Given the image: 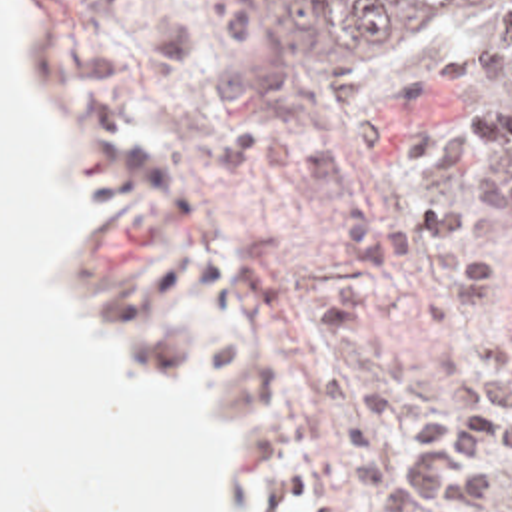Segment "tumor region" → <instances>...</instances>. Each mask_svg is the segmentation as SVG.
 Masks as SVG:
<instances>
[{"label":"tumor region","mask_w":512,"mask_h":512,"mask_svg":"<svg viewBox=\"0 0 512 512\" xmlns=\"http://www.w3.org/2000/svg\"><path fill=\"white\" fill-rule=\"evenodd\" d=\"M274 41L334 63L394 35L452 27L498 71L512 99V0H260Z\"/></svg>","instance_id":"obj_1"}]
</instances>
